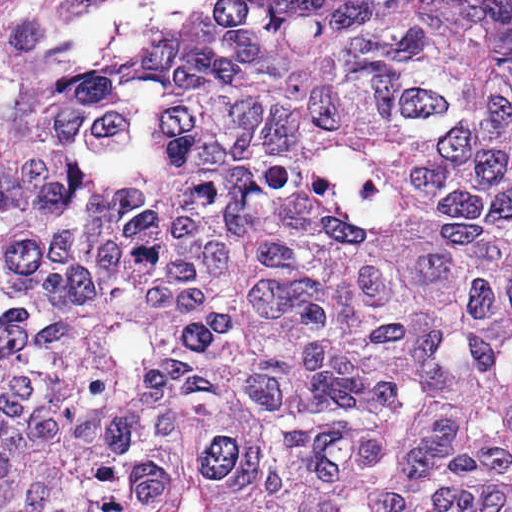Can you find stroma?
<instances>
[{"label": "stroma", "mask_w": 512, "mask_h": 512, "mask_svg": "<svg viewBox=\"0 0 512 512\" xmlns=\"http://www.w3.org/2000/svg\"><path fill=\"white\" fill-rule=\"evenodd\" d=\"M130 1L58 0L56 4L38 11L33 16L25 19V21L38 23L50 38V36L69 26L98 18ZM18 19L21 20L20 17Z\"/></svg>", "instance_id": "1"}]
</instances>
